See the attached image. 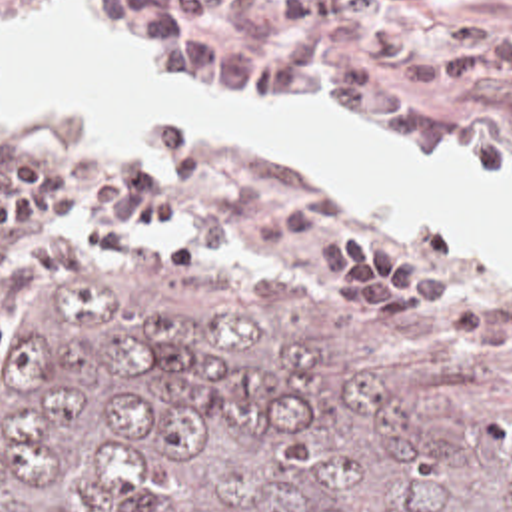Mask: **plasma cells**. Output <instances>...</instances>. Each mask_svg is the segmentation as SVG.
I'll list each match as a JSON object with an SVG mask.
<instances>
[{
    "instance_id": "1",
    "label": "plasma cells",
    "mask_w": 512,
    "mask_h": 512,
    "mask_svg": "<svg viewBox=\"0 0 512 512\" xmlns=\"http://www.w3.org/2000/svg\"><path fill=\"white\" fill-rule=\"evenodd\" d=\"M371 5L441 11V0H85L103 33L215 95L345 119L413 158H485V123L423 95L511 87L512 27L477 17L427 43Z\"/></svg>"
}]
</instances>
